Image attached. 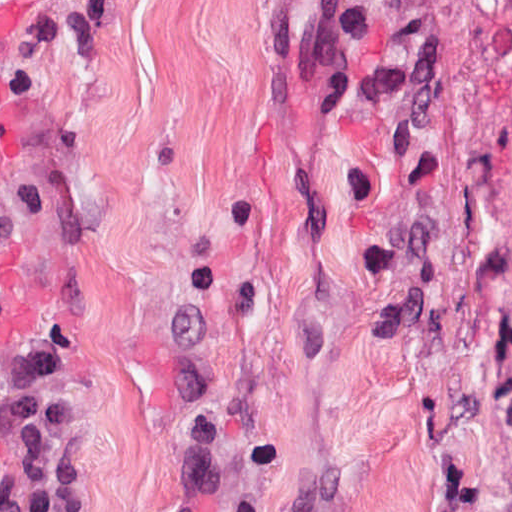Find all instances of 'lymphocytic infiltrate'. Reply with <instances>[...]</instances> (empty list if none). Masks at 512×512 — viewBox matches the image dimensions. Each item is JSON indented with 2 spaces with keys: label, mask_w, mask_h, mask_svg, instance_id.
Here are the masks:
<instances>
[{
  "label": "lymphocytic infiltrate",
  "mask_w": 512,
  "mask_h": 512,
  "mask_svg": "<svg viewBox=\"0 0 512 512\" xmlns=\"http://www.w3.org/2000/svg\"><path fill=\"white\" fill-rule=\"evenodd\" d=\"M499 402L512 433V330L506 338L504 354L499 363Z\"/></svg>",
  "instance_id": "lymphocytic-infiltrate-1"
}]
</instances>
